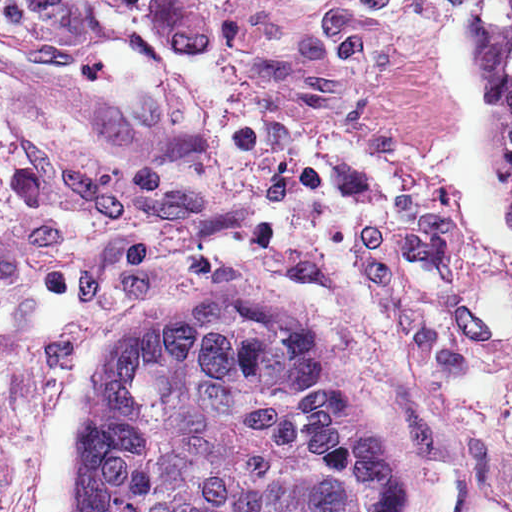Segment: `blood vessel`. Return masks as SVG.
Wrapping results in <instances>:
<instances>
[{"label": "blood vessel", "instance_id": "1", "mask_svg": "<svg viewBox=\"0 0 512 512\" xmlns=\"http://www.w3.org/2000/svg\"><path fill=\"white\" fill-rule=\"evenodd\" d=\"M0 66L68 103H106L121 93L107 72L85 68L38 37L16 28L0 0Z\"/></svg>", "mask_w": 512, "mask_h": 512}]
</instances>
